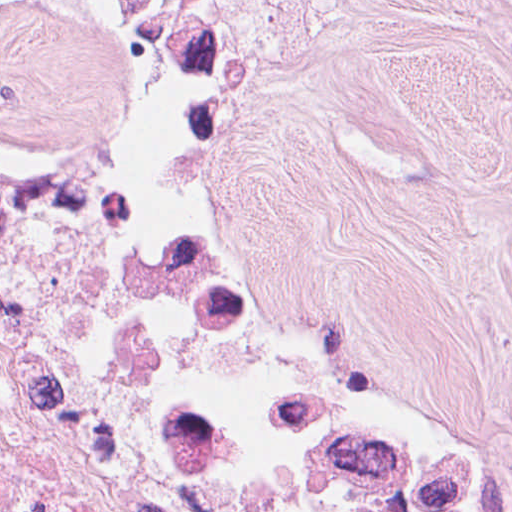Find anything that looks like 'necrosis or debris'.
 Segmentation results:
<instances>
[{
	"label": "necrosis or debris",
	"instance_id": "1",
	"mask_svg": "<svg viewBox=\"0 0 512 512\" xmlns=\"http://www.w3.org/2000/svg\"><path fill=\"white\" fill-rule=\"evenodd\" d=\"M0 512H512V452L113 99L0 116Z\"/></svg>",
	"mask_w": 512,
	"mask_h": 512
}]
</instances>
